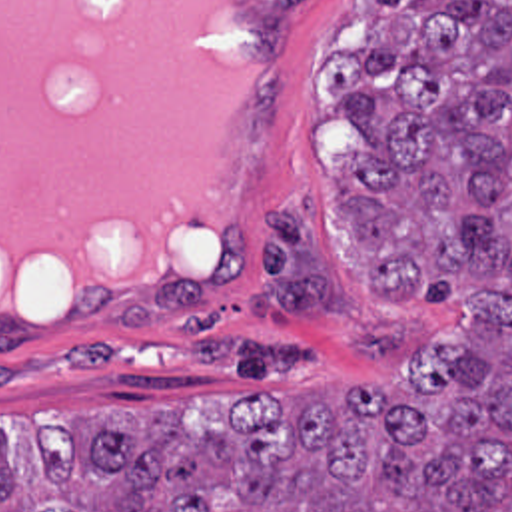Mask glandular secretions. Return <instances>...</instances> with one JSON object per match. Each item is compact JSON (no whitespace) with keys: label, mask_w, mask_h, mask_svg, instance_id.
Returning <instances> with one entry per match:
<instances>
[{"label":"glandular secretions","mask_w":512,"mask_h":512,"mask_svg":"<svg viewBox=\"0 0 512 512\" xmlns=\"http://www.w3.org/2000/svg\"><path fill=\"white\" fill-rule=\"evenodd\" d=\"M257 88L235 0H0V314L197 272Z\"/></svg>","instance_id":"obj_1"}]
</instances>
